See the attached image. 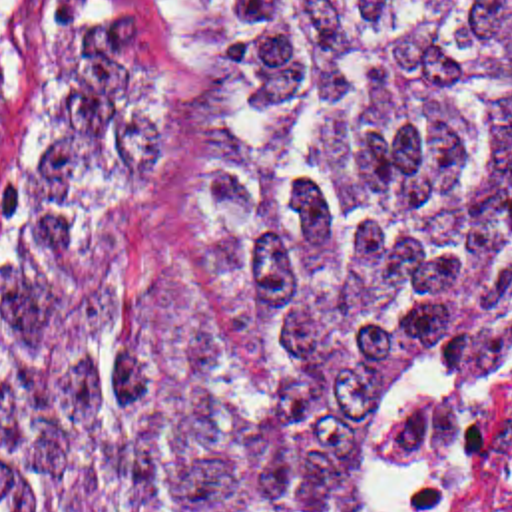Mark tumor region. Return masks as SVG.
I'll return each mask as SVG.
<instances>
[{
	"label": "tumor region",
	"instance_id": "1",
	"mask_svg": "<svg viewBox=\"0 0 512 512\" xmlns=\"http://www.w3.org/2000/svg\"><path fill=\"white\" fill-rule=\"evenodd\" d=\"M512 400V0H106L0 326V512H267L349 412Z\"/></svg>",
	"mask_w": 512,
	"mask_h": 512
}]
</instances>
